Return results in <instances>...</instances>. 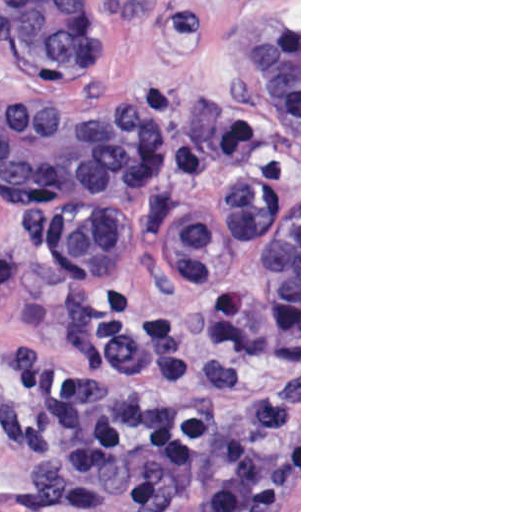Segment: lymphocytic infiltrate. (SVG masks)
I'll return each instance as SVG.
<instances>
[{"label": "lymphocytic infiltrate", "instance_id": "f902f5d3", "mask_svg": "<svg viewBox=\"0 0 512 512\" xmlns=\"http://www.w3.org/2000/svg\"><path fill=\"white\" fill-rule=\"evenodd\" d=\"M227 186L186 214L178 273L203 291L199 368L237 414L172 393L182 371L177 317L125 291L90 313L74 362L41 349L11 368L19 429L38 447L25 498L35 512H266L281 436L274 344L250 305L267 156L256 123L224 132Z\"/></svg>", "mask_w": 512, "mask_h": 512}]
</instances>
